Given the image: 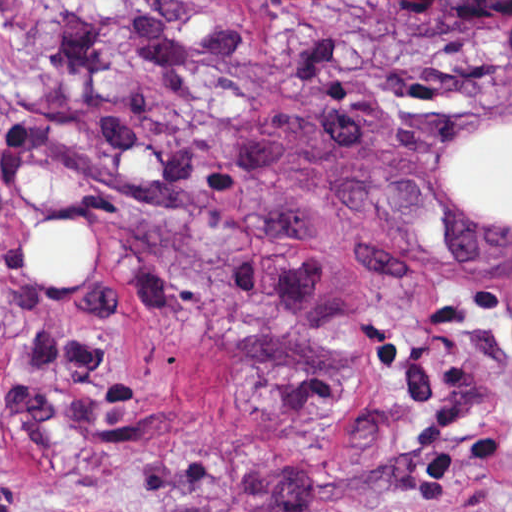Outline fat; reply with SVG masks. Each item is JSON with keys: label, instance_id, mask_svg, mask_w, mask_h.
Listing matches in <instances>:
<instances>
[{"label": "fat", "instance_id": "53f6f03d", "mask_svg": "<svg viewBox=\"0 0 512 512\" xmlns=\"http://www.w3.org/2000/svg\"><path fill=\"white\" fill-rule=\"evenodd\" d=\"M459 205L512 226V123L471 142L450 182ZM40 233L19 251L14 266L32 288L90 293L95 276V239L71 219Z\"/></svg>", "mask_w": 512, "mask_h": 512}]
</instances>
